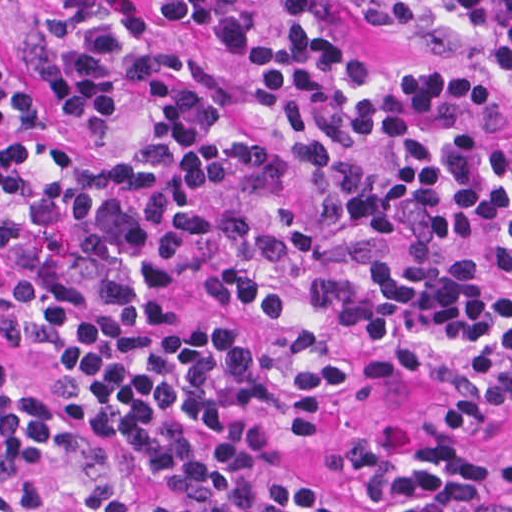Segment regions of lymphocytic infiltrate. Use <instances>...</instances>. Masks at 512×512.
<instances>
[{
	"label": "lymphocytic infiltrate",
	"mask_w": 512,
	"mask_h": 512,
	"mask_svg": "<svg viewBox=\"0 0 512 512\" xmlns=\"http://www.w3.org/2000/svg\"><path fill=\"white\" fill-rule=\"evenodd\" d=\"M62 0L41 83L75 149L0 109V512H512V378L334 425L386 359L512 362V0Z\"/></svg>",
	"instance_id": "obj_1"
}]
</instances>
